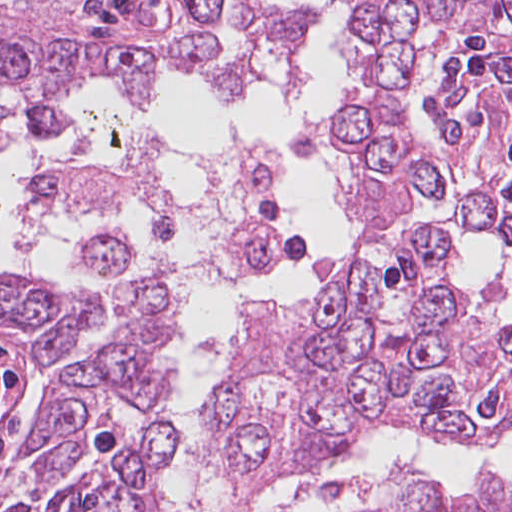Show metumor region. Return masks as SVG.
<instances>
[{"label": "tumor region", "instance_id": "obj_1", "mask_svg": "<svg viewBox=\"0 0 512 512\" xmlns=\"http://www.w3.org/2000/svg\"><path fill=\"white\" fill-rule=\"evenodd\" d=\"M365 240L345 279L296 308L247 305L203 416L211 462L237 485L275 489L329 472L388 429L489 443L512 428V318L456 272L455 249L415 217L450 208L459 227L512 245V124L347 180ZM279 234L248 221L188 269L116 291L97 343L85 300L36 278L0 290V324L26 334L49 386L21 418L0 512H188L161 488L175 445L142 414L166 381L192 286L265 271ZM363 512H512V487L467 490L393 477L347 485Z\"/></svg>", "mask_w": 512, "mask_h": 512}]
</instances>
